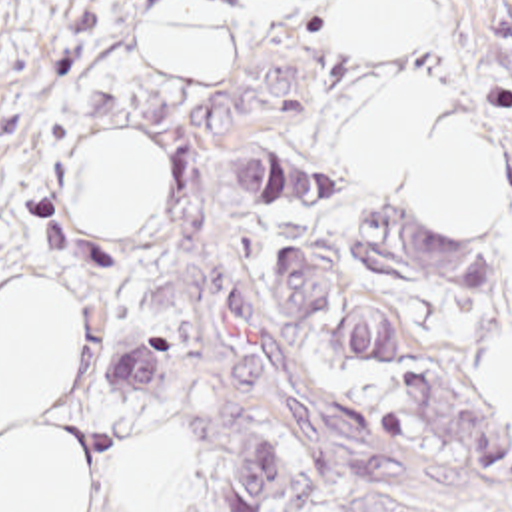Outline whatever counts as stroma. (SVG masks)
<instances>
[{"label":"stroma","instance_id":"35a3bbf8","mask_svg":"<svg viewBox=\"0 0 512 512\" xmlns=\"http://www.w3.org/2000/svg\"><path fill=\"white\" fill-rule=\"evenodd\" d=\"M165 0H19L0 42V296L43 278L81 318V364L53 415L91 461V512H127L135 453L177 437L187 509L235 512L213 485L269 443L291 485L263 512H318L350 489L444 512H512V410L468 370L512 342V0H436V36L400 50L338 44L336 0H225L217 80H175L145 50ZM414 80L470 104L496 136L504 216L452 218L344 166V126ZM129 136L167 158L151 218L71 216L63 172L87 138ZM285 144L330 200L233 202L243 144ZM438 224L492 252V290H410L360 270V216ZM312 244L342 276L312 320L265 288L283 246ZM380 308L400 340L386 370H342L328 322ZM159 334V398L121 390L119 356Z\"/></svg>","mask_w":512,"mask_h":512}]
</instances>
